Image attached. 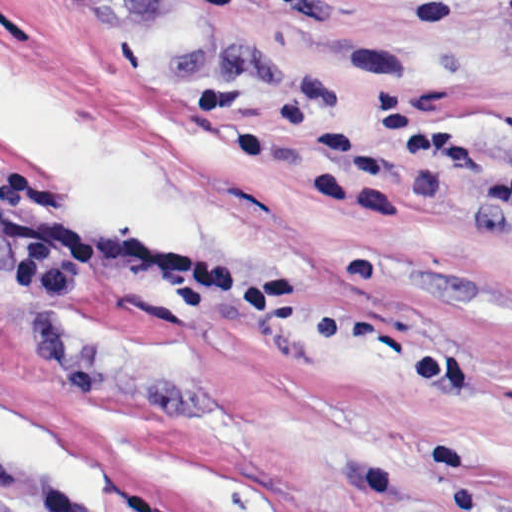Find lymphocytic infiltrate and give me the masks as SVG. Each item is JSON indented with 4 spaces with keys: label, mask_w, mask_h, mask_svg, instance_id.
Here are the masks:
<instances>
[{
    "label": "lymphocytic infiltrate",
    "mask_w": 512,
    "mask_h": 512,
    "mask_svg": "<svg viewBox=\"0 0 512 512\" xmlns=\"http://www.w3.org/2000/svg\"><path fill=\"white\" fill-rule=\"evenodd\" d=\"M202 1L268 5L290 13L326 10L318 0ZM190 98L196 107H219L234 115L225 144L234 157L253 167H267L279 152L298 148L304 154V189L312 199L367 213L388 212L410 171L470 200L512 231V168L447 152L393 99L372 103L370 113L377 126L394 135V143H389L364 128L329 122L307 101H284L276 119L264 122L244 87L202 89ZM0 512H15L1 490Z\"/></svg>",
    "instance_id": "1"
}]
</instances>
